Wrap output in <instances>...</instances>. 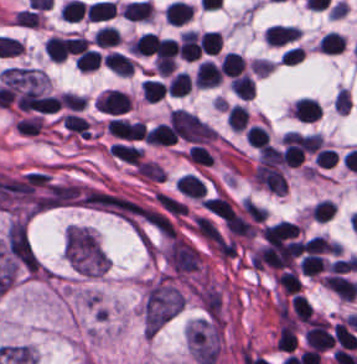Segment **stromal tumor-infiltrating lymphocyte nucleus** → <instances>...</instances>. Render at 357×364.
<instances>
[{
  "mask_svg": "<svg viewBox=\"0 0 357 364\" xmlns=\"http://www.w3.org/2000/svg\"><path fill=\"white\" fill-rule=\"evenodd\" d=\"M300 35L299 30L290 25H270L264 29L263 38L269 45H282Z\"/></svg>",
  "mask_w": 357,
  "mask_h": 364,
  "instance_id": "stromal-tumor-infiltrating-lymphocyte-nucleus-1",
  "label": "stromal tumor-infiltrating lymphocyte nucleus"
},
{
  "mask_svg": "<svg viewBox=\"0 0 357 364\" xmlns=\"http://www.w3.org/2000/svg\"><path fill=\"white\" fill-rule=\"evenodd\" d=\"M193 80L197 86L213 87L220 82V74L214 63L209 60H202L195 70Z\"/></svg>",
  "mask_w": 357,
  "mask_h": 364,
  "instance_id": "stromal-tumor-infiltrating-lymphocyte-nucleus-2",
  "label": "stromal tumor-infiltrating lymphocyte nucleus"
},
{
  "mask_svg": "<svg viewBox=\"0 0 357 364\" xmlns=\"http://www.w3.org/2000/svg\"><path fill=\"white\" fill-rule=\"evenodd\" d=\"M109 151L117 159L131 165H139L142 154L141 149L126 143L114 142L109 146Z\"/></svg>",
  "mask_w": 357,
  "mask_h": 364,
  "instance_id": "stromal-tumor-infiltrating-lymphocyte-nucleus-3",
  "label": "stromal tumor-infiltrating lymphocyte nucleus"
},
{
  "mask_svg": "<svg viewBox=\"0 0 357 364\" xmlns=\"http://www.w3.org/2000/svg\"><path fill=\"white\" fill-rule=\"evenodd\" d=\"M344 41L341 34L329 31L324 34L317 45L321 54H335L343 49Z\"/></svg>",
  "mask_w": 357,
  "mask_h": 364,
  "instance_id": "stromal-tumor-infiltrating-lymphocyte-nucleus-4",
  "label": "stromal tumor-infiltrating lymphocyte nucleus"
},
{
  "mask_svg": "<svg viewBox=\"0 0 357 364\" xmlns=\"http://www.w3.org/2000/svg\"><path fill=\"white\" fill-rule=\"evenodd\" d=\"M218 68L221 74L233 77L239 75L243 71L244 60L235 53L229 51L223 56L222 60L218 65Z\"/></svg>",
  "mask_w": 357,
  "mask_h": 364,
  "instance_id": "stromal-tumor-infiltrating-lymphocyte-nucleus-5",
  "label": "stromal tumor-infiltrating lymphocyte nucleus"
},
{
  "mask_svg": "<svg viewBox=\"0 0 357 364\" xmlns=\"http://www.w3.org/2000/svg\"><path fill=\"white\" fill-rule=\"evenodd\" d=\"M233 95L244 100H251L254 93V82L244 75L233 76L231 83Z\"/></svg>",
  "mask_w": 357,
  "mask_h": 364,
  "instance_id": "stromal-tumor-infiltrating-lymphocyte-nucleus-6",
  "label": "stromal tumor-infiltrating lymphocyte nucleus"
},
{
  "mask_svg": "<svg viewBox=\"0 0 357 364\" xmlns=\"http://www.w3.org/2000/svg\"><path fill=\"white\" fill-rule=\"evenodd\" d=\"M203 54H217L222 48V37L217 32H203L197 39Z\"/></svg>",
  "mask_w": 357,
  "mask_h": 364,
  "instance_id": "stromal-tumor-infiltrating-lymphocyte-nucleus-7",
  "label": "stromal tumor-infiltrating lymphocyte nucleus"
},
{
  "mask_svg": "<svg viewBox=\"0 0 357 364\" xmlns=\"http://www.w3.org/2000/svg\"><path fill=\"white\" fill-rule=\"evenodd\" d=\"M46 53L52 61H62L67 56V39L52 35L47 39Z\"/></svg>",
  "mask_w": 357,
  "mask_h": 364,
  "instance_id": "stromal-tumor-infiltrating-lymphocyte-nucleus-8",
  "label": "stromal tumor-infiltrating lymphocyte nucleus"
},
{
  "mask_svg": "<svg viewBox=\"0 0 357 364\" xmlns=\"http://www.w3.org/2000/svg\"><path fill=\"white\" fill-rule=\"evenodd\" d=\"M76 63L81 71L88 72L99 69L101 63L100 53L87 48L77 55Z\"/></svg>",
  "mask_w": 357,
  "mask_h": 364,
  "instance_id": "stromal-tumor-infiltrating-lymphocyte-nucleus-9",
  "label": "stromal tumor-infiltrating lymphocyte nucleus"
},
{
  "mask_svg": "<svg viewBox=\"0 0 357 364\" xmlns=\"http://www.w3.org/2000/svg\"><path fill=\"white\" fill-rule=\"evenodd\" d=\"M247 118L248 111L244 107L234 104L226 115V122L232 131H242Z\"/></svg>",
  "mask_w": 357,
  "mask_h": 364,
  "instance_id": "stromal-tumor-infiltrating-lymphocyte-nucleus-10",
  "label": "stromal tumor-infiltrating lymphocyte nucleus"
},
{
  "mask_svg": "<svg viewBox=\"0 0 357 364\" xmlns=\"http://www.w3.org/2000/svg\"><path fill=\"white\" fill-rule=\"evenodd\" d=\"M300 271L306 276H315L326 266L320 255L306 254L299 261Z\"/></svg>",
  "mask_w": 357,
  "mask_h": 364,
  "instance_id": "stromal-tumor-infiltrating-lymphocyte-nucleus-11",
  "label": "stromal tumor-infiltrating lymphocyte nucleus"
},
{
  "mask_svg": "<svg viewBox=\"0 0 357 364\" xmlns=\"http://www.w3.org/2000/svg\"><path fill=\"white\" fill-rule=\"evenodd\" d=\"M191 82V78L183 73H176L172 75L165 92L170 96H183Z\"/></svg>",
  "mask_w": 357,
  "mask_h": 364,
  "instance_id": "stromal-tumor-infiltrating-lymphocyte-nucleus-12",
  "label": "stromal tumor-infiltrating lymphocyte nucleus"
},
{
  "mask_svg": "<svg viewBox=\"0 0 357 364\" xmlns=\"http://www.w3.org/2000/svg\"><path fill=\"white\" fill-rule=\"evenodd\" d=\"M300 248L304 253L311 254H322L326 252H330L331 245L325 239L320 236H312L307 241L301 244Z\"/></svg>",
  "mask_w": 357,
  "mask_h": 364,
  "instance_id": "stromal-tumor-infiltrating-lymphocyte-nucleus-13",
  "label": "stromal tumor-infiltrating lymphocyte nucleus"
},
{
  "mask_svg": "<svg viewBox=\"0 0 357 364\" xmlns=\"http://www.w3.org/2000/svg\"><path fill=\"white\" fill-rule=\"evenodd\" d=\"M244 137L252 147L257 149L269 142L268 132L259 125H252Z\"/></svg>",
  "mask_w": 357,
  "mask_h": 364,
  "instance_id": "stromal-tumor-infiltrating-lymphocyte-nucleus-14",
  "label": "stromal tumor-infiltrating lymphocyte nucleus"
},
{
  "mask_svg": "<svg viewBox=\"0 0 357 364\" xmlns=\"http://www.w3.org/2000/svg\"><path fill=\"white\" fill-rule=\"evenodd\" d=\"M332 206L333 203L325 199L312 206L310 210L312 220L325 222L331 216Z\"/></svg>",
  "mask_w": 357,
  "mask_h": 364,
  "instance_id": "stromal-tumor-infiltrating-lymphocyte-nucleus-15",
  "label": "stromal tumor-infiltrating lymphocyte nucleus"
}]
</instances>
